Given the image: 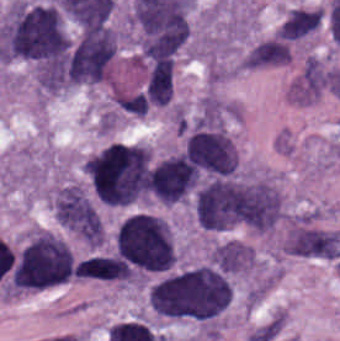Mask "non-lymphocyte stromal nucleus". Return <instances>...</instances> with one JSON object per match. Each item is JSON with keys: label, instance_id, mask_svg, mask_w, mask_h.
<instances>
[{"label": "non-lymphocyte stromal nucleus", "instance_id": "obj_1", "mask_svg": "<svg viewBox=\"0 0 340 341\" xmlns=\"http://www.w3.org/2000/svg\"><path fill=\"white\" fill-rule=\"evenodd\" d=\"M54 211L59 224L80 238L102 235V218L88 192L78 183L57 191Z\"/></svg>", "mask_w": 340, "mask_h": 341}]
</instances>
